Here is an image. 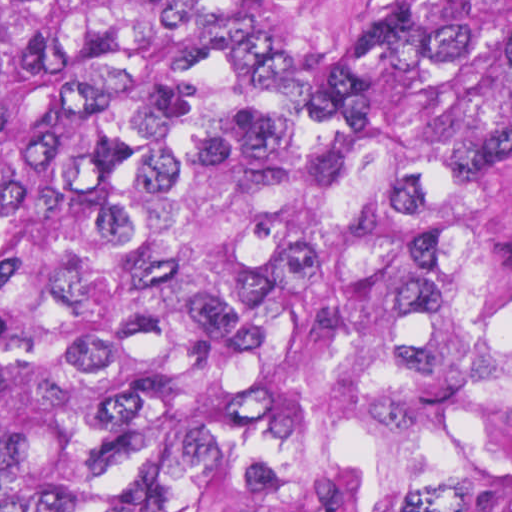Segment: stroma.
I'll list each match as a JSON object with an SVG mask.
<instances>
[{
	"instance_id": "35a3bbf8",
	"label": "stroma",
	"mask_w": 512,
	"mask_h": 512,
	"mask_svg": "<svg viewBox=\"0 0 512 512\" xmlns=\"http://www.w3.org/2000/svg\"><path fill=\"white\" fill-rule=\"evenodd\" d=\"M320 99L330 61L353 30L420 0H279Z\"/></svg>"
}]
</instances>
